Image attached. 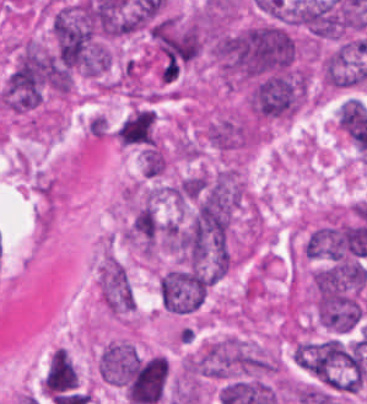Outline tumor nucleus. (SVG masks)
I'll return each mask as SVG.
<instances>
[{"label":"tumor nucleus","instance_id":"3d1891a8","mask_svg":"<svg viewBox=\"0 0 367 404\" xmlns=\"http://www.w3.org/2000/svg\"><path fill=\"white\" fill-rule=\"evenodd\" d=\"M162 223L153 203L143 201L133 208L127 223V240L144 256L153 257L161 244Z\"/></svg>","mask_w":367,"mask_h":404},{"label":"tumor nucleus","instance_id":"2f306a5c","mask_svg":"<svg viewBox=\"0 0 367 404\" xmlns=\"http://www.w3.org/2000/svg\"><path fill=\"white\" fill-rule=\"evenodd\" d=\"M275 355L238 337L212 338L189 356V375L216 378L258 376L277 371Z\"/></svg>","mask_w":367,"mask_h":404},{"label":"tumor nucleus","instance_id":"8087334f","mask_svg":"<svg viewBox=\"0 0 367 404\" xmlns=\"http://www.w3.org/2000/svg\"><path fill=\"white\" fill-rule=\"evenodd\" d=\"M114 138L120 145L145 146L154 143V123L152 110L133 108L118 123Z\"/></svg>","mask_w":367,"mask_h":404},{"label":"tumor nucleus","instance_id":"5ab6c2c4","mask_svg":"<svg viewBox=\"0 0 367 404\" xmlns=\"http://www.w3.org/2000/svg\"><path fill=\"white\" fill-rule=\"evenodd\" d=\"M201 130L211 146L226 152L242 150L255 140L253 122L234 108L213 109L203 118Z\"/></svg>","mask_w":367,"mask_h":404},{"label":"tumor nucleus","instance_id":"8643909e","mask_svg":"<svg viewBox=\"0 0 367 404\" xmlns=\"http://www.w3.org/2000/svg\"><path fill=\"white\" fill-rule=\"evenodd\" d=\"M214 279L205 268L189 264L162 270L157 279L161 305L173 312L197 310Z\"/></svg>","mask_w":367,"mask_h":404},{"label":"tumor nucleus","instance_id":"c2bd9aea","mask_svg":"<svg viewBox=\"0 0 367 404\" xmlns=\"http://www.w3.org/2000/svg\"><path fill=\"white\" fill-rule=\"evenodd\" d=\"M168 165L167 153L163 145H144L141 153L142 176L158 178Z\"/></svg>","mask_w":367,"mask_h":404},{"label":"tumor nucleus","instance_id":"2083b535","mask_svg":"<svg viewBox=\"0 0 367 404\" xmlns=\"http://www.w3.org/2000/svg\"><path fill=\"white\" fill-rule=\"evenodd\" d=\"M134 366V347L126 339H113L98 351L96 368L103 383L123 388Z\"/></svg>","mask_w":367,"mask_h":404},{"label":"tumor nucleus","instance_id":"2cbd58db","mask_svg":"<svg viewBox=\"0 0 367 404\" xmlns=\"http://www.w3.org/2000/svg\"><path fill=\"white\" fill-rule=\"evenodd\" d=\"M98 296L113 316H120L132 310L134 294L126 268L113 253H105L98 266Z\"/></svg>","mask_w":367,"mask_h":404}]
</instances>
